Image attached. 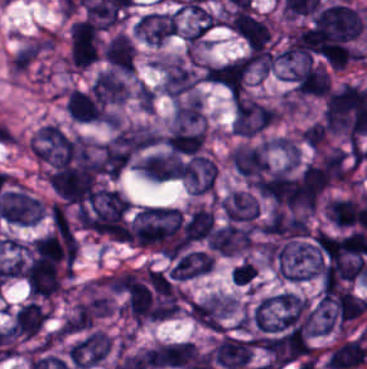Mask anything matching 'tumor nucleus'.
<instances>
[{
  "mask_svg": "<svg viewBox=\"0 0 367 369\" xmlns=\"http://www.w3.org/2000/svg\"><path fill=\"white\" fill-rule=\"evenodd\" d=\"M275 110L276 107L262 101L240 96L233 104V131L251 135L273 121Z\"/></svg>",
  "mask_w": 367,
  "mask_h": 369,
  "instance_id": "obj_1",
  "label": "tumor nucleus"
},
{
  "mask_svg": "<svg viewBox=\"0 0 367 369\" xmlns=\"http://www.w3.org/2000/svg\"><path fill=\"white\" fill-rule=\"evenodd\" d=\"M112 346V339L99 329H92L69 347L67 354L74 367L88 368L99 364Z\"/></svg>",
  "mask_w": 367,
  "mask_h": 369,
  "instance_id": "obj_2",
  "label": "tumor nucleus"
},
{
  "mask_svg": "<svg viewBox=\"0 0 367 369\" xmlns=\"http://www.w3.org/2000/svg\"><path fill=\"white\" fill-rule=\"evenodd\" d=\"M156 67L161 88L173 101L194 87L198 79L181 58L159 60Z\"/></svg>",
  "mask_w": 367,
  "mask_h": 369,
  "instance_id": "obj_3",
  "label": "tumor nucleus"
},
{
  "mask_svg": "<svg viewBox=\"0 0 367 369\" xmlns=\"http://www.w3.org/2000/svg\"><path fill=\"white\" fill-rule=\"evenodd\" d=\"M190 194L212 191L217 166L207 154H193L180 169Z\"/></svg>",
  "mask_w": 367,
  "mask_h": 369,
  "instance_id": "obj_4",
  "label": "tumor nucleus"
},
{
  "mask_svg": "<svg viewBox=\"0 0 367 369\" xmlns=\"http://www.w3.org/2000/svg\"><path fill=\"white\" fill-rule=\"evenodd\" d=\"M214 260L208 252L192 250L180 255L169 269L171 279L187 280L209 272Z\"/></svg>",
  "mask_w": 367,
  "mask_h": 369,
  "instance_id": "obj_5",
  "label": "tumor nucleus"
},
{
  "mask_svg": "<svg viewBox=\"0 0 367 369\" xmlns=\"http://www.w3.org/2000/svg\"><path fill=\"white\" fill-rule=\"evenodd\" d=\"M101 53L106 63L115 69L125 73H132V43L123 33L112 35L103 45Z\"/></svg>",
  "mask_w": 367,
  "mask_h": 369,
  "instance_id": "obj_6",
  "label": "tumor nucleus"
},
{
  "mask_svg": "<svg viewBox=\"0 0 367 369\" xmlns=\"http://www.w3.org/2000/svg\"><path fill=\"white\" fill-rule=\"evenodd\" d=\"M91 92L94 97L106 103L122 104L127 97L125 82L109 69H102L96 74Z\"/></svg>",
  "mask_w": 367,
  "mask_h": 369,
  "instance_id": "obj_7",
  "label": "tumor nucleus"
},
{
  "mask_svg": "<svg viewBox=\"0 0 367 369\" xmlns=\"http://www.w3.org/2000/svg\"><path fill=\"white\" fill-rule=\"evenodd\" d=\"M47 312L35 302L28 301L15 310L12 330L19 337H32L46 320Z\"/></svg>",
  "mask_w": 367,
  "mask_h": 369,
  "instance_id": "obj_8",
  "label": "tumor nucleus"
},
{
  "mask_svg": "<svg viewBox=\"0 0 367 369\" xmlns=\"http://www.w3.org/2000/svg\"><path fill=\"white\" fill-rule=\"evenodd\" d=\"M63 104L69 116L77 122H93L94 105L90 89L72 87L65 92Z\"/></svg>",
  "mask_w": 367,
  "mask_h": 369,
  "instance_id": "obj_9",
  "label": "tumor nucleus"
},
{
  "mask_svg": "<svg viewBox=\"0 0 367 369\" xmlns=\"http://www.w3.org/2000/svg\"><path fill=\"white\" fill-rule=\"evenodd\" d=\"M300 136L309 147L318 150L327 136V130L320 121H313L304 127Z\"/></svg>",
  "mask_w": 367,
  "mask_h": 369,
  "instance_id": "obj_10",
  "label": "tumor nucleus"
},
{
  "mask_svg": "<svg viewBox=\"0 0 367 369\" xmlns=\"http://www.w3.org/2000/svg\"><path fill=\"white\" fill-rule=\"evenodd\" d=\"M257 274V269L251 261H241L231 269V281L235 285H246Z\"/></svg>",
  "mask_w": 367,
  "mask_h": 369,
  "instance_id": "obj_11",
  "label": "tumor nucleus"
}]
</instances>
